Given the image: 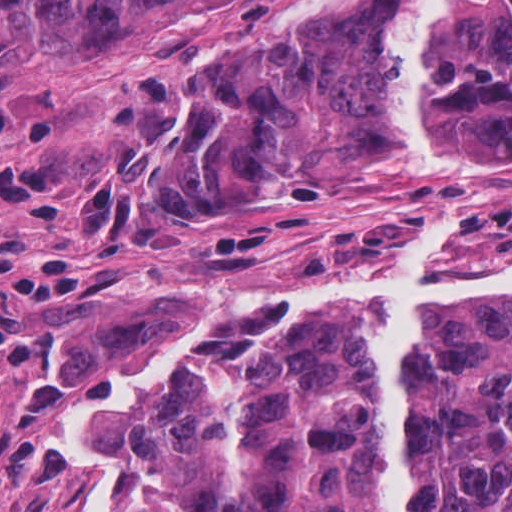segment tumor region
<instances>
[{"mask_svg": "<svg viewBox=\"0 0 512 512\" xmlns=\"http://www.w3.org/2000/svg\"><path fill=\"white\" fill-rule=\"evenodd\" d=\"M46 47L98 49L184 0H7ZM394 0L344 5L311 44L226 48L162 160V195L204 223L274 186L387 150L429 176L512 158V0H456L434 161L387 57ZM408 512H512V297L425 314L404 361ZM64 429L108 484V512H374V386L354 329L328 312L178 323L121 402Z\"/></svg>", "mask_w": 512, "mask_h": 512, "instance_id": "e687c5a6", "label": "tumor region"}]
</instances>
